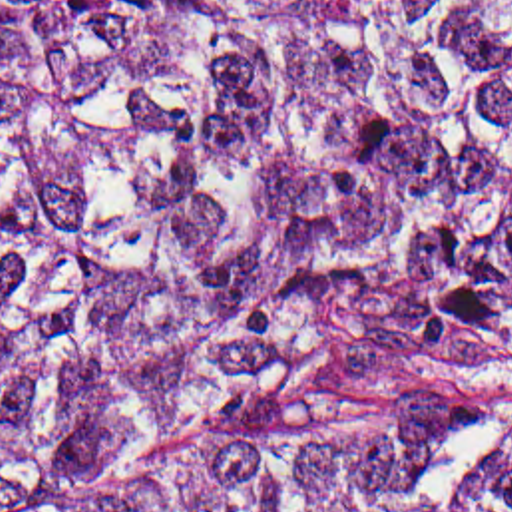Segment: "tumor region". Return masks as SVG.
Here are the masks:
<instances>
[{
    "label": "tumor region",
    "mask_w": 512,
    "mask_h": 512,
    "mask_svg": "<svg viewBox=\"0 0 512 512\" xmlns=\"http://www.w3.org/2000/svg\"><path fill=\"white\" fill-rule=\"evenodd\" d=\"M0 512H512V0H0Z\"/></svg>",
    "instance_id": "e687c5a6"
}]
</instances>
